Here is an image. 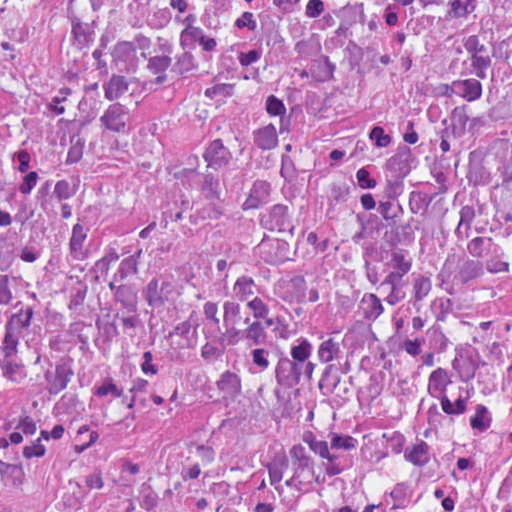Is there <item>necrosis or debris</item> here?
I'll return each instance as SVG.
<instances>
[{"instance_id": "obj_1", "label": "necrosis or debris", "mask_w": 512, "mask_h": 512, "mask_svg": "<svg viewBox=\"0 0 512 512\" xmlns=\"http://www.w3.org/2000/svg\"><path fill=\"white\" fill-rule=\"evenodd\" d=\"M1 512H512V1H1Z\"/></svg>"}]
</instances>
